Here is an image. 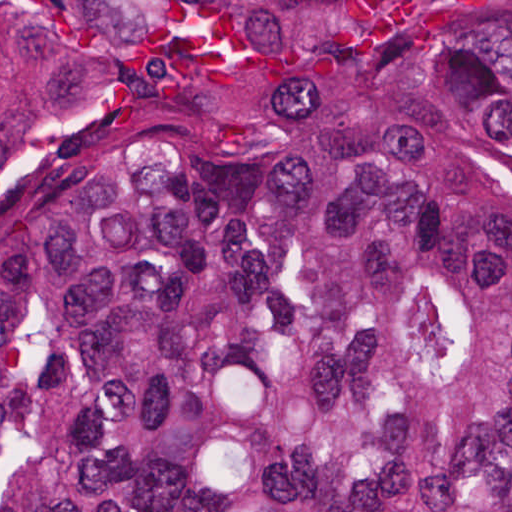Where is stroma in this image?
Returning <instances> with one entry per match:
<instances>
[{"instance_id": "1", "label": "stroma", "mask_w": 512, "mask_h": 512, "mask_svg": "<svg viewBox=\"0 0 512 512\" xmlns=\"http://www.w3.org/2000/svg\"><path fill=\"white\" fill-rule=\"evenodd\" d=\"M38 20L41 0H28ZM0 512H1V0H0Z\"/></svg>"}]
</instances>
